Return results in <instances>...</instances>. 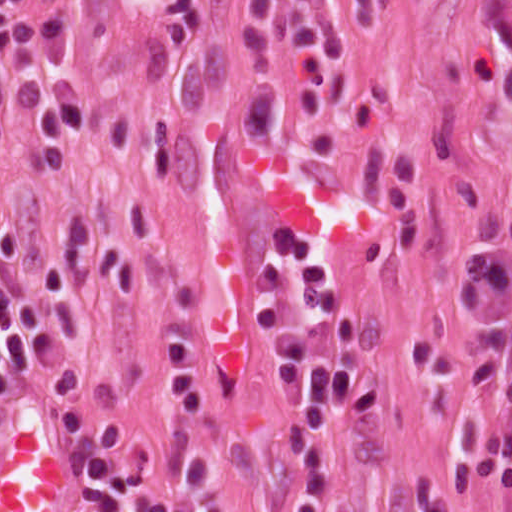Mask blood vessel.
Instances as JSON below:
<instances>
[{"label": "blood vessel", "instance_id": "obj_1", "mask_svg": "<svg viewBox=\"0 0 512 512\" xmlns=\"http://www.w3.org/2000/svg\"><path fill=\"white\" fill-rule=\"evenodd\" d=\"M50 402L36 396L0 428V512H78V459Z\"/></svg>", "mask_w": 512, "mask_h": 512}]
</instances>
